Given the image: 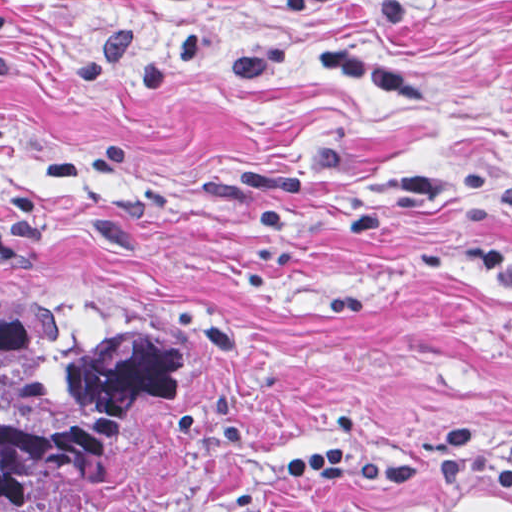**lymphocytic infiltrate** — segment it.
<instances>
[{
	"label": "lymphocytic infiltrate",
	"instance_id": "1",
	"mask_svg": "<svg viewBox=\"0 0 512 512\" xmlns=\"http://www.w3.org/2000/svg\"><path fill=\"white\" fill-rule=\"evenodd\" d=\"M431 478L512 491V466L464 433L383 451H318L285 463L283 470V481L301 487L338 480L405 485Z\"/></svg>",
	"mask_w": 512,
	"mask_h": 512
}]
</instances>
